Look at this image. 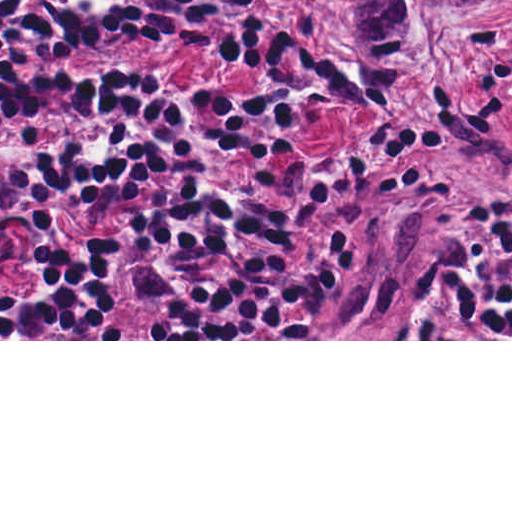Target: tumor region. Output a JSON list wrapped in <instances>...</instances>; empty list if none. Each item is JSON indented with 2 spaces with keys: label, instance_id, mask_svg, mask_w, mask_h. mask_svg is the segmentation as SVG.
Returning a JSON list of instances; mask_svg holds the SVG:
<instances>
[{
  "label": "tumor region",
  "instance_id": "obj_1",
  "mask_svg": "<svg viewBox=\"0 0 512 512\" xmlns=\"http://www.w3.org/2000/svg\"><path fill=\"white\" fill-rule=\"evenodd\" d=\"M345 20L355 39L382 57L402 54L431 0H325ZM362 78L374 97L402 87L382 66H365ZM512 156L503 131L487 127L467 146L457 148L416 174L404 189L390 221L366 254L365 266L425 225L434 211L462 187L484 177Z\"/></svg>",
  "mask_w": 512,
  "mask_h": 512
}]
</instances>
